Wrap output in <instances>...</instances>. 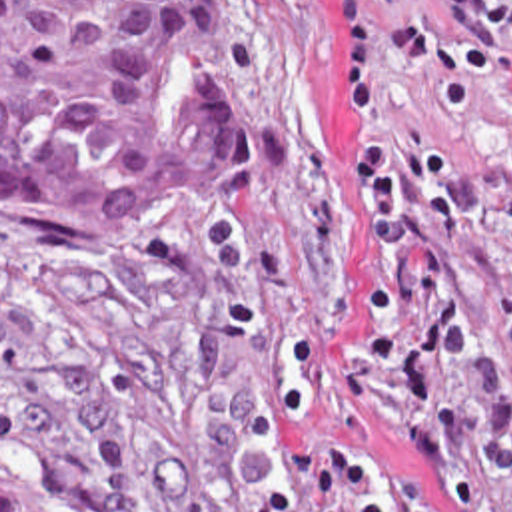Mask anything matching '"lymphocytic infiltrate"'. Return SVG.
<instances>
[{"mask_svg": "<svg viewBox=\"0 0 512 512\" xmlns=\"http://www.w3.org/2000/svg\"><path fill=\"white\" fill-rule=\"evenodd\" d=\"M336 115L352 197L376 251L358 247L360 323L340 364L354 410L431 470L463 512L453 378L471 359L461 269L473 191L457 135L489 85L512 87V0H334ZM308 466L336 512H437L388 466L322 436Z\"/></svg>", "mask_w": 512, "mask_h": 512, "instance_id": "obj_1", "label": "lymphocytic infiltrate"}]
</instances>
